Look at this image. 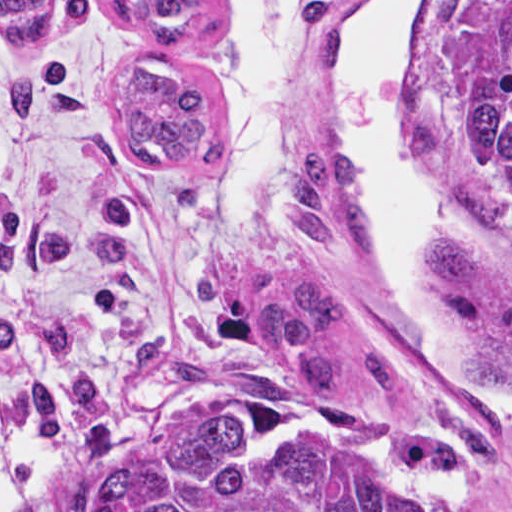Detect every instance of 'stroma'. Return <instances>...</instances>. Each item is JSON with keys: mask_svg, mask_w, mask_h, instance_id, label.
<instances>
[{"mask_svg": "<svg viewBox=\"0 0 512 512\" xmlns=\"http://www.w3.org/2000/svg\"><path fill=\"white\" fill-rule=\"evenodd\" d=\"M0 1H53L34 44L0 30V453L20 443L44 453L35 491L73 478L110 436L208 392L231 415L242 459L334 438L458 512H512V421L429 369L385 284L378 237L375 249H349L316 246L292 223L291 231L233 227L214 206L223 156L209 167H139L124 156L126 66L164 55L166 45L131 34L110 1L213 6L212 27L182 47L227 125L228 101L195 54L220 35L226 0ZM359 1L299 0L294 159L346 151L334 127V28ZM464 1L512 0L413 8L399 45L400 132L411 166L447 194L434 243L480 249L512 294V237L467 198L450 162L447 56ZM303 279L352 293L403 361L401 394L373 390L354 331L339 339L348 374L341 397L319 396L300 361L269 352L247 295ZM433 279L458 321L467 372L498 337L499 320Z\"/></svg>", "mask_w": 512, "mask_h": 512, "instance_id": "obj_1", "label": "stroma"}]
</instances>
